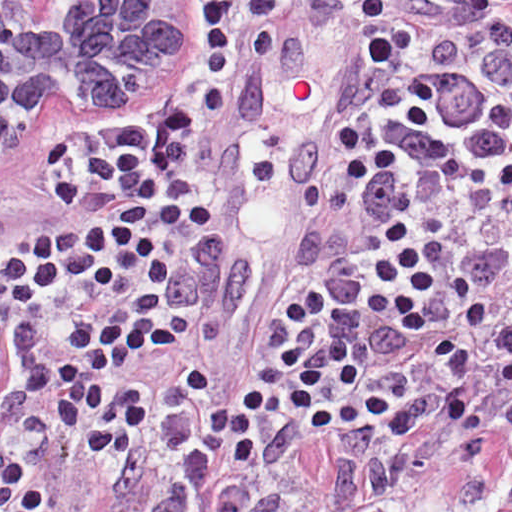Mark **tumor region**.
Segmentation results:
<instances>
[{"label": "tumor region", "instance_id": "e687c5a6", "mask_svg": "<svg viewBox=\"0 0 512 512\" xmlns=\"http://www.w3.org/2000/svg\"><path fill=\"white\" fill-rule=\"evenodd\" d=\"M408 3V1H399L398 3V6H397V10H396V13L397 14H400L401 11L404 9V7L406 6V4ZM371 84V83H370ZM370 84L369 86L367 87V89L365 90V92L363 93V95L360 97V100L363 104V106L365 107V104H366V101L368 99V95H369V89H370ZM403 177L411 180V170H409ZM181 260H185V255L183 256V258ZM260 373V370L258 372V374ZM257 374V375H258ZM456 464H459L460 463H456Z\"/></svg>", "mask_w": 512, "mask_h": 512}]
</instances>
